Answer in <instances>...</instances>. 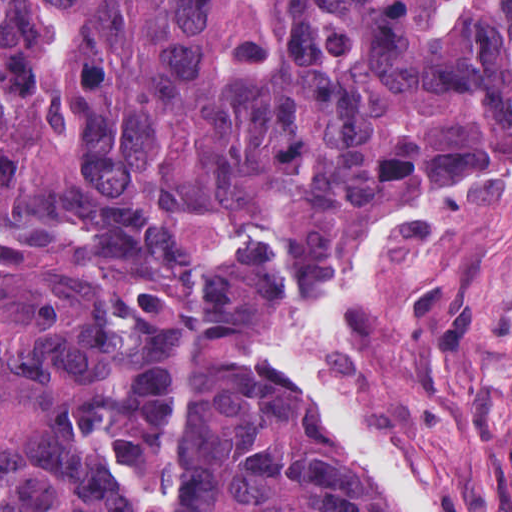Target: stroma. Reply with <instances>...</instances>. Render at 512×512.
<instances>
[{
	"mask_svg": "<svg viewBox=\"0 0 512 512\" xmlns=\"http://www.w3.org/2000/svg\"><path fill=\"white\" fill-rule=\"evenodd\" d=\"M216 327L363 508L387 512L353 462L265 374L266 325ZM335 382L368 412L380 451L427 512H512V181L368 266L355 286Z\"/></svg>",
	"mask_w": 512,
	"mask_h": 512,
	"instance_id": "stroma-1",
	"label": "stroma"
}]
</instances>
